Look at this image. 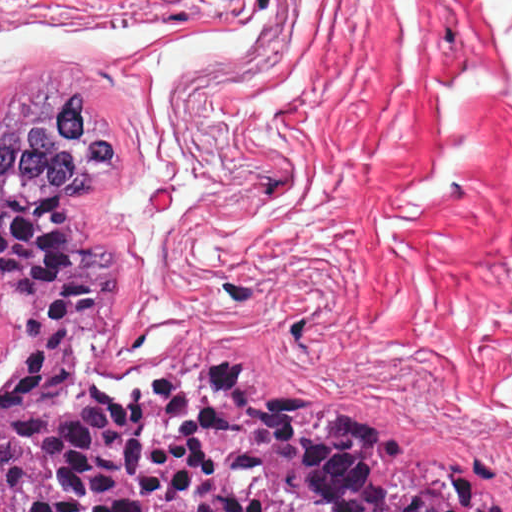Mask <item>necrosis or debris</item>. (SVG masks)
Returning a JSON list of instances; mask_svg holds the SVG:
<instances>
[{
  "label": "necrosis or debris",
  "instance_id": "necrosis-or-debris-1",
  "mask_svg": "<svg viewBox=\"0 0 512 512\" xmlns=\"http://www.w3.org/2000/svg\"><path fill=\"white\" fill-rule=\"evenodd\" d=\"M8 291L0 287V371L9 362L19 340V324L16 316L7 310Z\"/></svg>",
  "mask_w": 512,
  "mask_h": 512
}]
</instances>
